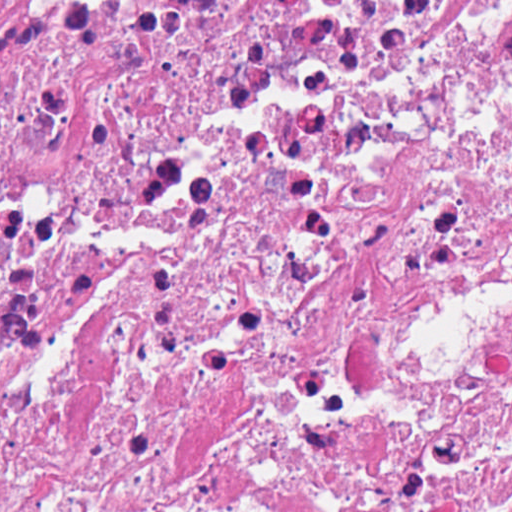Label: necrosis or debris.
Instances as JSON below:
<instances>
[{
  "label": "necrosis or debris",
  "mask_w": 512,
  "mask_h": 512,
  "mask_svg": "<svg viewBox=\"0 0 512 512\" xmlns=\"http://www.w3.org/2000/svg\"><path fill=\"white\" fill-rule=\"evenodd\" d=\"M0 512H512V0H0Z\"/></svg>",
  "instance_id": "4bbe7bcc"
}]
</instances>
